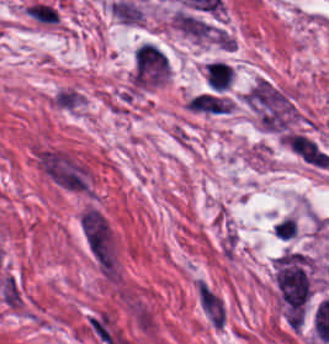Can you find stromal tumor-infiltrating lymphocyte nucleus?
Returning <instances> with one entry per match:
<instances>
[{"instance_id": "1", "label": "stromal tumor-infiltrating lymphocyte nucleus", "mask_w": 329, "mask_h": 344, "mask_svg": "<svg viewBox=\"0 0 329 344\" xmlns=\"http://www.w3.org/2000/svg\"><path fill=\"white\" fill-rule=\"evenodd\" d=\"M206 78L210 88L221 91L231 85L232 68L230 64L226 62L214 60L208 63Z\"/></svg>"}, {"instance_id": "2", "label": "stromal tumor-infiltrating lymphocyte nucleus", "mask_w": 329, "mask_h": 344, "mask_svg": "<svg viewBox=\"0 0 329 344\" xmlns=\"http://www.w3.org/2000/svg\"><path fill=\"white\" fill-rule=\"evenodd\" d=\"M32 16L39 22L54 23L57 17L56 8L41 1H34L28 6Z\"/></svg>"}, {"instance_id": "3", "label": "stromal tumor-infiltrating lymphocyte nucleus", "mask_w": 329, "mask_h": 344, "mask_svg": "<svg viewBox=\"0 0 329 344\" xmlns=\"http://www.w3.org/2000/svg\"><path fill=\"white\" fill-rule=\"evenodd\" d=\"M278 227L280 230L282 240H289L293 239L298 227L292 224L290 221L285 219L284 217L280 218L278 221Z\"/></svg>"}]
</instances>
